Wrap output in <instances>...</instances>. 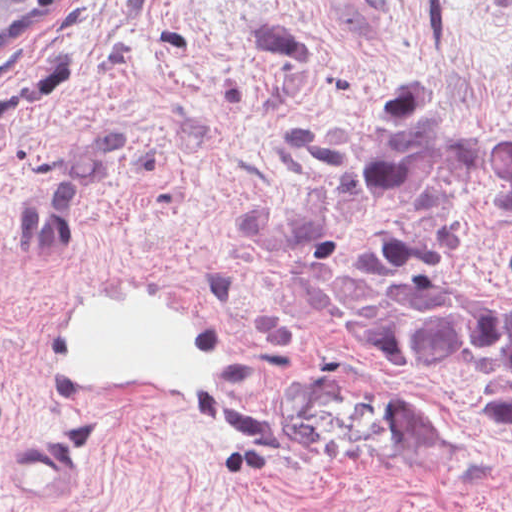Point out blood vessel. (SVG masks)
Listing matches in <instances>:
<instances>
[{"mask_svg": "<svg viewBox=\"0 0 512 512\" xmlns=\"http://www.w3.org/2000/svg\"><path fill=\"white\" fill-rule=\"evenodd\" d=\"M173 286L125 275L67 284L46 322L57 400L95 428L208 427L249 451L278 448V412L241 383L217 326L185 292L198 293ZM71 474L68 447L48 434L8 446L6 476L28 500L62 497Z\"/></svg>", "mask_w": 512, "mask_h": 512, "instance_id": "obj_1", "label": "blood vessel"}]
</instances>
